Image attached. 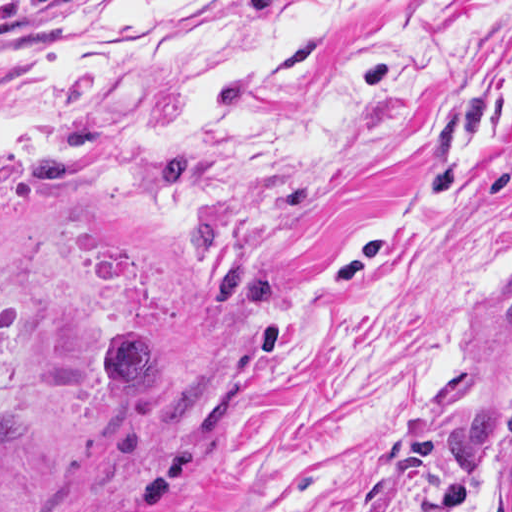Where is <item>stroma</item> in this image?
<instances>
[{
    "label": "stroma",
    "instance_id": "1",
    "mask_svg": "<svg viewBox=\"0 0 512 512\" xmlns=\"http://www.w3.org/2000/svg\"><path fill=\"white\" fill-rule=\"evenodd\" d=\"M93 1L0 0V79ZM285 61L320 144L157 133L0 184V512H510L505 442L461 502L434 463L512 405V0H350ZM177 145L204 176L147 198ZM204 218L275 300L218 308ZM126 327L237 385L216 427L166 435L163 378L107 434L104 348Z\"/></svg>",
    "mask_w": 512,
    "mask_h": 512
}]
</instances>
